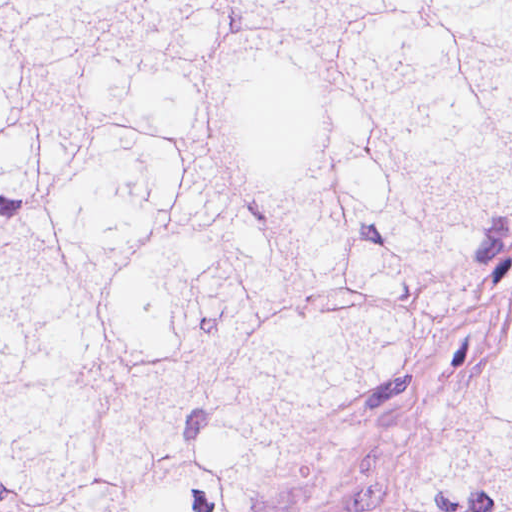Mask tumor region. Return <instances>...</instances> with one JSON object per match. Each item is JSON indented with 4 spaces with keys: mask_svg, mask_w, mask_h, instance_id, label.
<instances>
[{
    "mask_svg": "<svg viewBox=\"0 0 512 512\" xmlns=\"http://www.w3.org/2000/svg\"><path fill=\"white\" fill-rule=\"evenodd\" d=\"M512 220V1H0V512H283ZM403 512H512V328Z\"/></svg>",
    "mask_w": 512,
    "mask_h": 512,
    "instance_id": "tumor-region-1",
    "label": "tumor region"
}]
</instances>
